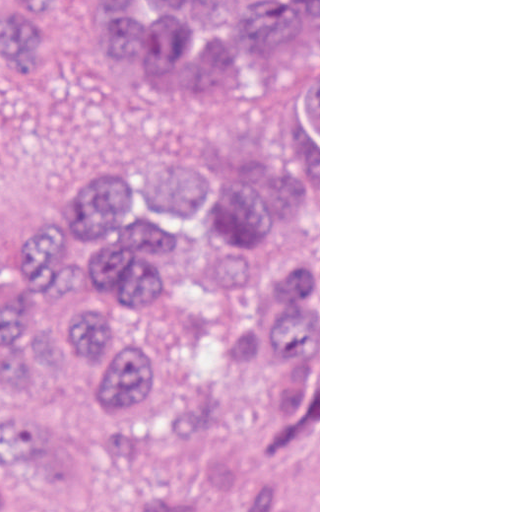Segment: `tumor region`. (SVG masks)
I'll use <instances>...</instances> for the list:
<instances>
[{
    "mask_svg": "<svg viewBox=\"0 0 512 512\" xmlns=\"http://www.w3.org/2000/svg\"><path fill=\"white\" fill-rule=\"evenodd\" d=\"M319 0H0V84L185 109L89 170L0 109V512H319Z\"/></svg>",
    "mask_w": 512,
    "mask_h": 512,
    "instance_id": "obj_1",
    "label": "tumor region"
}]
</instances>
